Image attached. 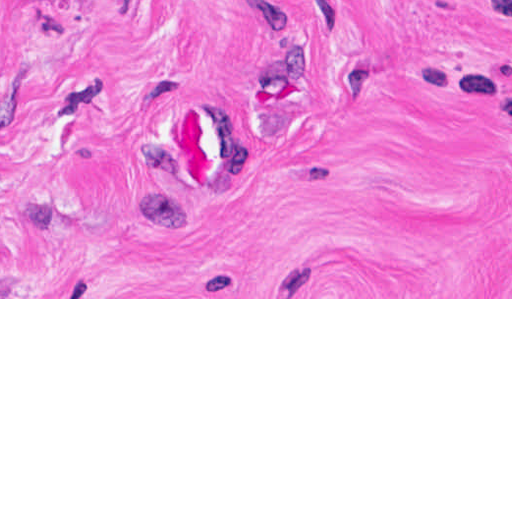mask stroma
Instances as JSON below:
<instances>
[{
	"mask_svg": "<svg viewBox=\"0 0 512 512\" xmlns=\"http://www.w3.org/2000/svg\"><path fill=\"white\" fill-rule=\"evenodd\" d=\"M0 299H512V0H0Z\"/></svg>",
	"mask_w": 512,
	"mask_h": 512,
	"instance_id": "1",
	"label": "stroma"
}]
</instances>
